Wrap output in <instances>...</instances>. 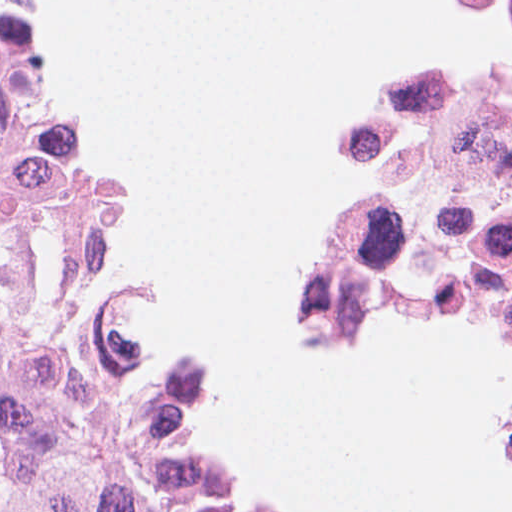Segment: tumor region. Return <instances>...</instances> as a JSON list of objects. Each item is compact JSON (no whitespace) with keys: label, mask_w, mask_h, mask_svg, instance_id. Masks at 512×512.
<instances>
[{"label":"tumor region","mask_w":512,"mask_h":512,"mask_svg":"<svg viewBox=\"0 0 512 512\" xmlns=\"http://www.w3.org/2000/svg\"><path fill=\"white\" fill-rule=\"evenodd\" d=\"M121 180L44 66L36 0H0V512H230L185 442L194 363L142 355L132 290H79ZM405 309L482 311L360 306L323 329L367 336ZM309 323L325 348L359 344Z\"/></svg>","instance_id":"tumor-region-1"}]
</instances>
